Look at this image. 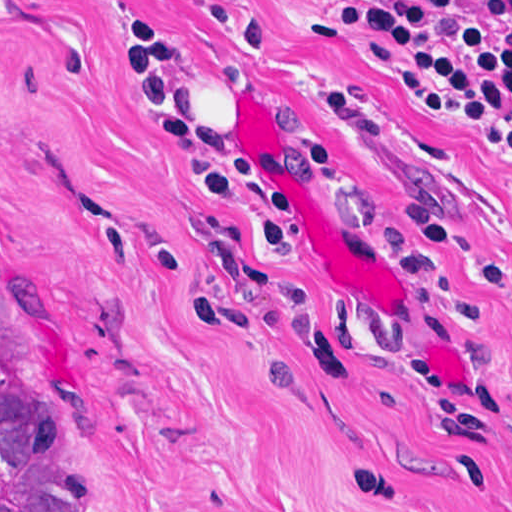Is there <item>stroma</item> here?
Returning <instances> with one entry per match:
<instances>
[{"instance_id": "stroma-1", "label": "stroma", "mask_w": 512, "mask_h": 512, "mask_svg": "<svg viewBox=\"0 0 512 512\" xmlns=\"http://www.w3.org/2000/svg\"><path fill=\"white\" fill-rule=\"evenodd\" d=\"M243 1L258 42L171 0H0L5 376L74 430L103 512H512V169L484 140L511 152L312 0ZM142 11L202 127L300 194L292 252L264 190L209 199L202 153L156 137L119 40ZM332 83L386 138L350 142Z\"/></svg>"}]
</instances>
